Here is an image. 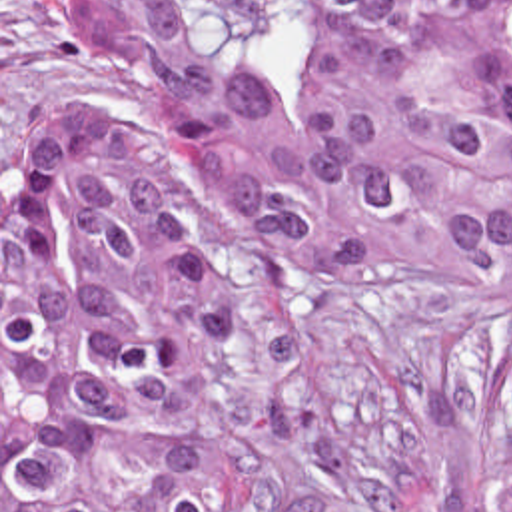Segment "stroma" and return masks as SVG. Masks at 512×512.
I'll list each match as a JSON object with an SVG mask.
<instances>
[{"label": "stroma", "mask_w": 512, "mask_h": 512, "mask_svg": "<svg viewBox=\"0 0 512 512\" xmlns=\"http://www.w3.org/2000/svg\"><path fill=\"white\" fill-rule=\"evenodd\" d=\"M98 81L64 57L48 0H0V512L8 137L28 115L78 103L144 135L156 159L172 151L126 53H106ZM214 263L216 438L256 512H481V434L505 343L479 297L435 271L284 281L262 237L228 217L214 229Z\"/></svg>", "instance_id": "1"}]
</instances>
